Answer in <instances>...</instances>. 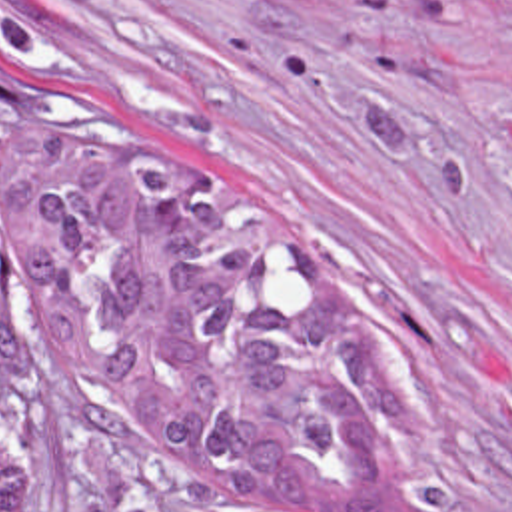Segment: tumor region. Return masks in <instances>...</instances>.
I'll use <instances>...</instances> for the list:
<instances>
[{
	"instance_id": "tumor-region-1",
	"label": "tumor region",
	"mask_w": 512,
	"mask_h": 512,
	"mask_svg": "<svg viewBox=\"0 0 512 512\" xmlns=\"http://www.w3.org/2000/svg\"><path fill=\"white\" fill-rule=\"evenodd\" d=\"M0 332L191 500L389 512L383 366L239 186L39 78H0ZM0 512H39L0 396Z\"/></svg>"
}]
</instances>
